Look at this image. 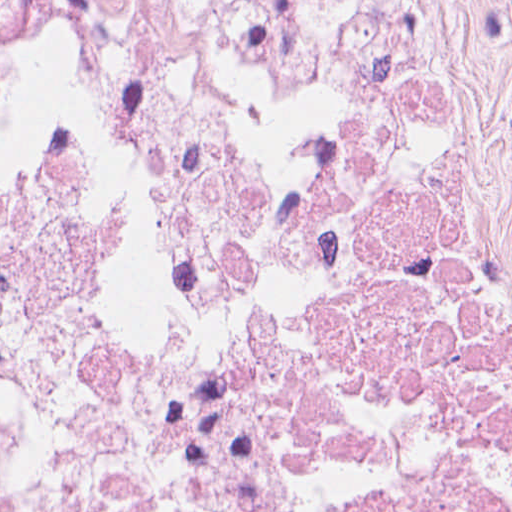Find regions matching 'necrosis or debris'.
<instances>
[{
  "label": "necrosis or debris",
  "mask_w": 512,
  "mask_h": 512,
  "mask_svg": "<svg viewBox=\"0 0 512 512\" xmlns=\"http://www.w3.org/2000/svg\"><path fill=\"white\" fill-rule=\"evenodd\" d=\"M511 403L399 0H0V512H471Z\"/></svg>",
  "instance_id": "4bbe7bcc"
}]
</instances>
